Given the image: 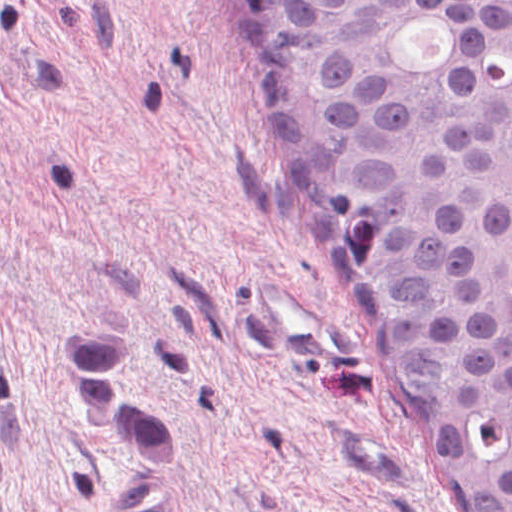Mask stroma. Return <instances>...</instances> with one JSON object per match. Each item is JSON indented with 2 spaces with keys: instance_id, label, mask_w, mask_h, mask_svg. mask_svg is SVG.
Listing matches in <instances>:
<instances>
[{
  "instance_id": "stroma-1",
  "label": "stroma",
  "mask_w": 512,
  "mask_h": 512,
  "mask_svg": "<svg viewBox=\"0 0 512 512\" xmlns=\"http://www.w3.org/2000/svg\"><path fill=\"white\" fill-rule=\"evenodd\" d=\"M253 275L344 318L275 193L231 0H0V512H464L354 329L348 371L303 366ZM70 317L131 319L163 475L77 407Z\"/></svg>"
}]
</instances>
